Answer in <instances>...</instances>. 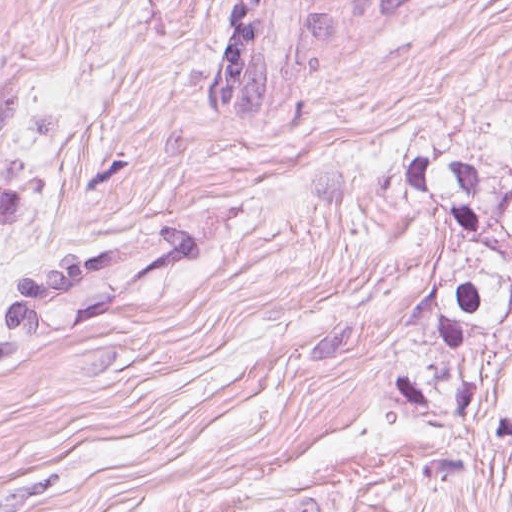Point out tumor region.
I'll return each instance as SVG.
<instances>
[{
  "mask_svg": "<svg viewBox=\"0 0 512 512\" xmlns=\"http://www.w3.org/2000/svg\"><path fill=\"white\" fill-rule=\"evenodd\" d=\"M448 1L231 0L208 103L202 96L220 121H252L337 57ZM386 183L441 234V277L388 364V405L415 428L512 448V420L489 400L512 357V165L485 150H429L391 168ZM247 226L232 213L207 215L114 249L16 269L1 293L0 360L34 336L96 317Z\"/></svg>",
  "mask_w": 512,
  "mask_h": 512,
  "instance_id": "e687c5a6",
  "label": "tumor region"
}]
</instances>
